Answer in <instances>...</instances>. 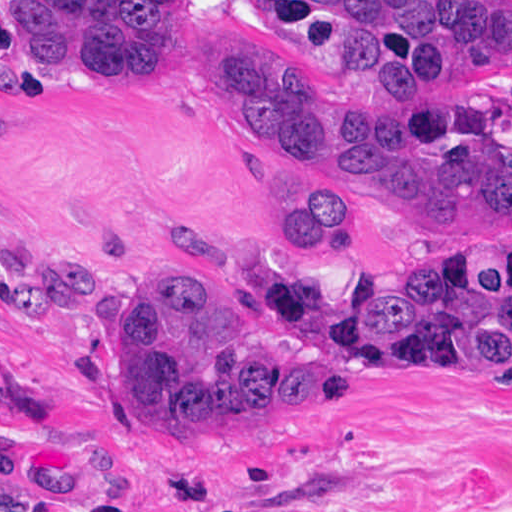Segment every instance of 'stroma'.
Masks as SVG:
<instances>
[{"label":"stroma","instance_id":"1","mask_svg":"<svg viewBox=\"0 0 512 512\" xmlns=\"http://www.w3.org/2000/svg\"><path fill=\"white\" fill-rule=\"evenodd\" d=\"M188 12L197 33L238 26L314 92L347 98L355 86L266 0H188ZM8 62L0 0V280L30 259L98 266L103 318L50 330L0 297V512H512V380L352 373L350 391L223 407L178 437L123 409L115 375V340L147 260H179L261 296L243 265L250 250H273L317 279L332 311L389 266L512 249V235L433 226L334 189L347 246L298 249L264 221L263 197L328 184L254 143L191 66L155 82L136 115L77 119L41 105ZM434 83L512 89V54Z\"/></svg>","mask_w":512,"mask_h":512}]
</instances>
